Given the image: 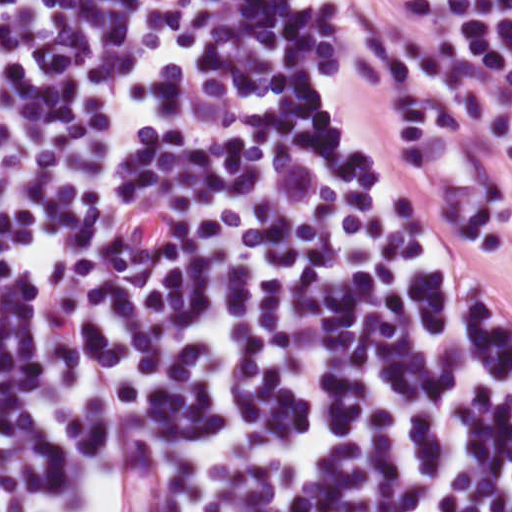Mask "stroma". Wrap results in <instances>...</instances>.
Instances as JSON below:
<instances>
[{
  "label": "stroma",
  "instance_id": "stroma-1",
  "mask_svg": "<svg viewBox=\"0 0 512 512\" xmlns=\"http://www.w3.org/2000/svg\"><path fill=\"white\" fill-rule=\"evenodd\" d=\"M165 493L157 473L153 474L140 486H138L130 496L119 506H125L140 500H144L159 494ZM118 507V508H119Z\"/></svg>",
  "mask_w": 512,
  "mask_h": 512
}]
</instances>
